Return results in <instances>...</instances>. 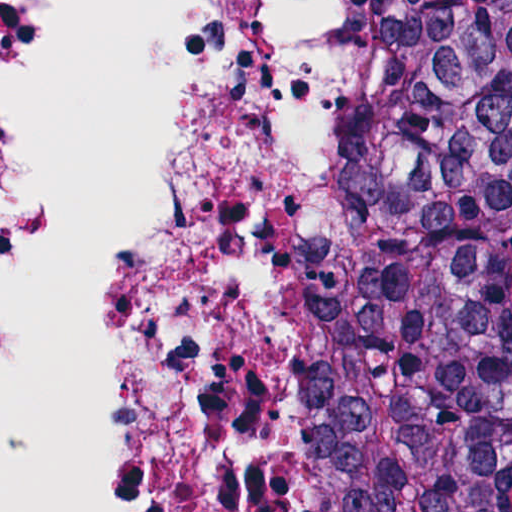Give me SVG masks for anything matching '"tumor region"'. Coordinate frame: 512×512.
<instances>
[{"label": "tumor region", "instance_id": "e687c5a6", "mask_svg": "<svg viewBox=\"0 0 512 512\" xmlns=\"http://www.w3.org/2000/svg\"><path fill=\"white\" fill-rule=\"evenodd\" d=\"M302 512H512L505 0H378V87L290 284Z\"/></svg>", "mask_w": 512, "mask_h": 512}]
</instances>
